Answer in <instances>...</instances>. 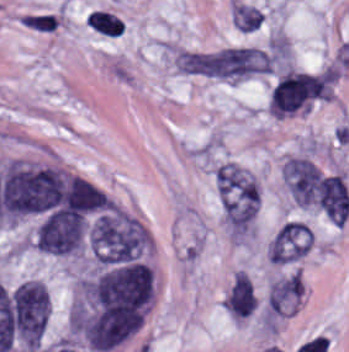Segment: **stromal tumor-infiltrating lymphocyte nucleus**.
I'll use <instances>...</instances> for the list:
<instances>
[{
    "label": "stromal tumor-infiltrating lymphocyte nucleus",
    "instance_id": "bc302bb0",
    "mask_svg": "<svg viewBox=\"0 0 349 352\" xmlns=\"http://www.w3.org/2000/svg\"><path fill=\"white\" fill-rule=\"evenodd\" d=\"M86 23L104 35L116 37L121 31L120 18L107 10L96 8L92 11Z\"/></svg>",
    "mask_w": 349,
    "mask_h": 352
},
{
    "label": "stromal tumor-infiltrating lymphocyte nucleus",
    "instance_id": "52c7bb5b",
    "mask_svg": "<svg viewBox=\"0 0 349 352\" xmlns=\"http://www.w3.org/2000/svg\"><path fill=\"white\" fill-rule=\"evenodd\" d=\"M27 26L34 29L51 31L57 25L55 13L41 12V13H23L20 20Z\"/></svg>",
    "mask_w": 349,
    "mask_h": 352
}]
</instances>
